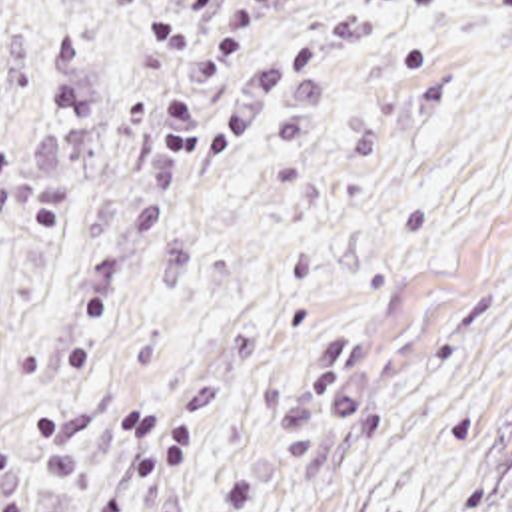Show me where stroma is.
Here are the masks:
<instances>
[{
  "instance_id": "obj_1",
  "label": "stroma",
  "mask_w": 512,
  "mask_h": 512,
  "mask_svg": "<svg viewBox=\"0 0 512 512\" xmlns=\"http://www.w3.org/2000/svg\"><path fill=\"white\" fill-rule=\"evenodd\" d=\"M0 512H512V0H0Z\"/></svg>"
}]
</instances>
